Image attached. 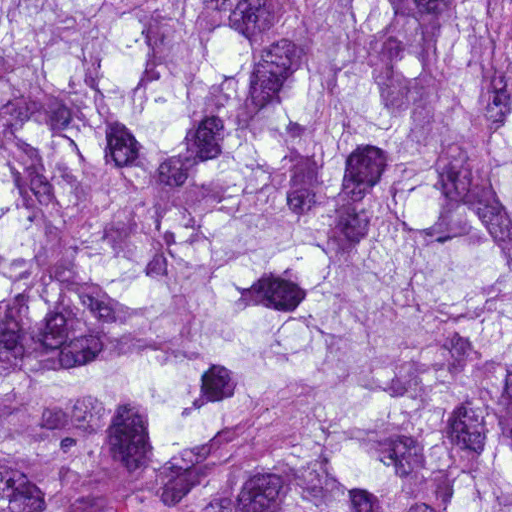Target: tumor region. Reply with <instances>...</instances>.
I'll return each mask as SVG.
<instances>
[{
    "label": "tumor region",
    "mask_w": 512,
    "mask_h": 512,
    "mask_svg": "<svg viewBox=\"0 0 512 512\" xmlns=\"http://www.w3.org/2000/svg\"><path fill=\"white\" fill-rule=\"evenodd\" d=\"M1 512H512V0H1Z\"/></svg>",
    "instance_id": "e687c5a6"
}]
</instances>
